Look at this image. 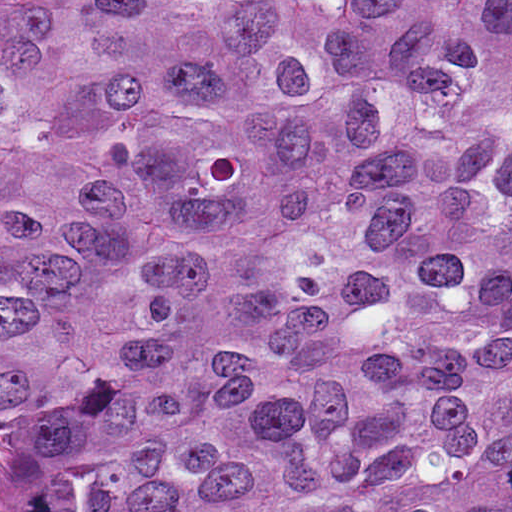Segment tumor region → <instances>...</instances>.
Instances as JSON below:
<instances>
[{"label": "tumor region", "instance_id": "obj_1", "mask_svg": "<svg viewBox=\"0 0 512 512\" xmlns=\"http://www.w3.org/2000/svg\"><path fill=\"white\" fill-rule=\"evenodd\" d=\"M21 512H512V0H0Z\"/></svg>", "mask_w": 512, "mask_h": 512}]
</instances>
